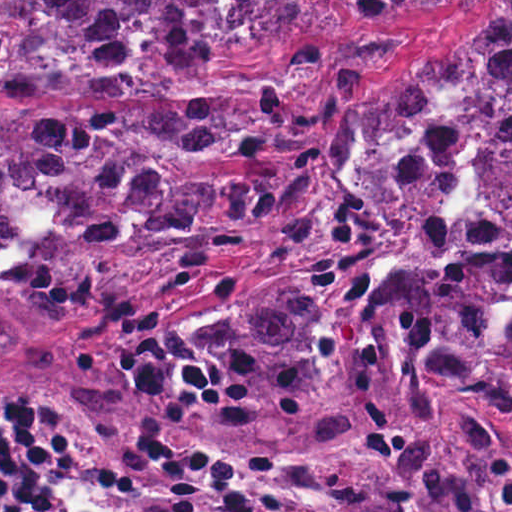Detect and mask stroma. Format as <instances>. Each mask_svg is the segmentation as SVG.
<instances>
[{
	"mask_svg": "<svg viewBox=\"0 0 512 512\" xmlns=\"http://www.w3.org/2000/svg\"><path fill=\"white\" fill-rule=\"evenodd\" d=\"M349 1L329 0V8L294 41L263 56L199 68L170 90H120L98 84H37L0 90V115H68L83 109H230L295 93L284 115L286 125L320 157L314 197L292 220L181 272L150 275L91 303L78 320L72 341L42 379H26L0 361L1 380L56 397L18 424L38 433L56 455L54 488L43 503L27 512H46L61 505L79 485L78 465L65 443L53 436L47 419L112 424L108 427L145 442L177 471L186 512H306L298 498L274 500L258 490L240 452L218 431L134 393L115 378L110 366L114 356L161 321L192 317L256 275L369 232L331 172L333 140L359 102L411 82L441 45L430 48L423 61L400 77L388 71L383 78L347 94L310 99L295 71L308 74L343 53L372 44L367 38L368 20L360 21L350 25L346 44L333 46L295 69V44L301 40L317 36L335 45L347 39ZM438 401L444 410L462 418L486 416L512 430V405L452 393ZM432 512H512V503L491 509L449 502L445 511Z\"/></svg>",
	"mask_w": 512,
	"mask_h": 512,
	"instance_id": "1",
	"label": "stroma"
}]
</instances>
